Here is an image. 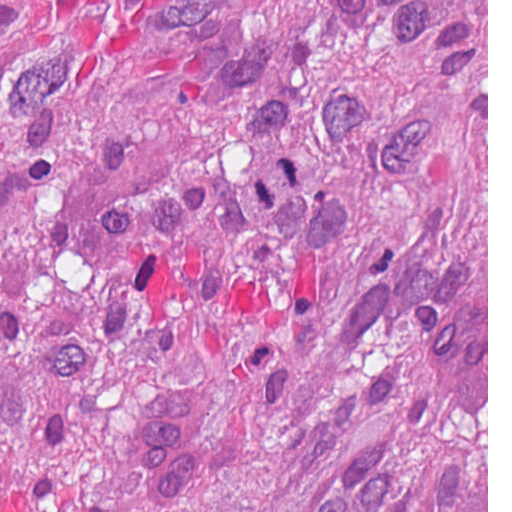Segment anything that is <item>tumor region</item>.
Here are the masks:
<instances>
[{
  "label": "tumor region",
  "mask_w": 512,
  "mask_h": 512,
  "mask_svg": "<svg viewBox=\"0 0 512 512\" xmlns=\"http://www.w3.org/2000/svg\"><path fill=\"white\" fill-rule=\"evenodd\" d=\"M440 281L487 367V0H0V512H487Z\"/></svg>",
  "instance_id": "e687c5a6"
}]
</instances>
